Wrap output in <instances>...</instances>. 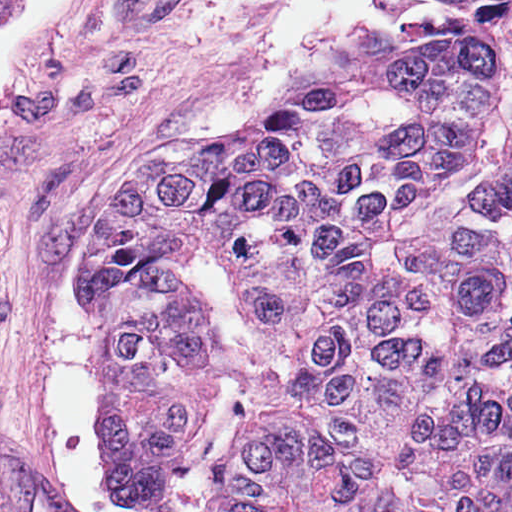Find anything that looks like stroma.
<instances>
[{"label": "stroma", "mask_w": 512, "mask_h": 512, "mask_svg": "<svg viewBox=\"0 0 512 512\" xmlns=\"http://www.w3.org/2000/svg\"><path fill=\"white\" fill-rule=\"evenodd\" d=\"M152 159L203 143L256 105L237 95L280 0H82Z\"/></svg>", "instance_id": "stroma-1"}]
</instances>
